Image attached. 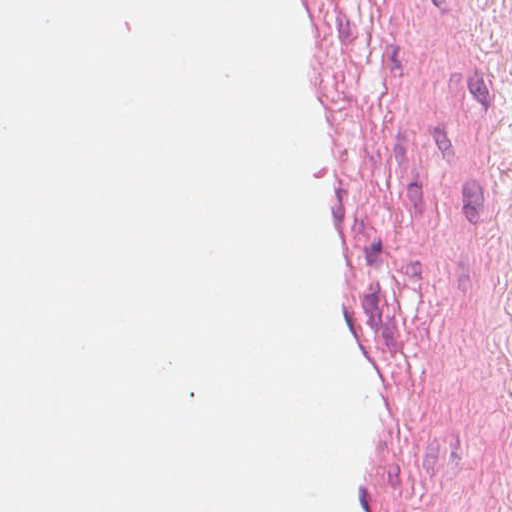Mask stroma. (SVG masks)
<instances>
[{"label": "stroma", "instance_id": "35a3bbf8", "mask_svg": "<svg viewBox=\"0 0 512 512\" xmlns=\"http://www.w3.org/2000/svg\"><path fill=\"white\" fill-rule=\"evenodd\" d=\"M419 512H512V77Z\"/></svg>", "mask_w": 512, "mask_h": 512}]
</instances>
